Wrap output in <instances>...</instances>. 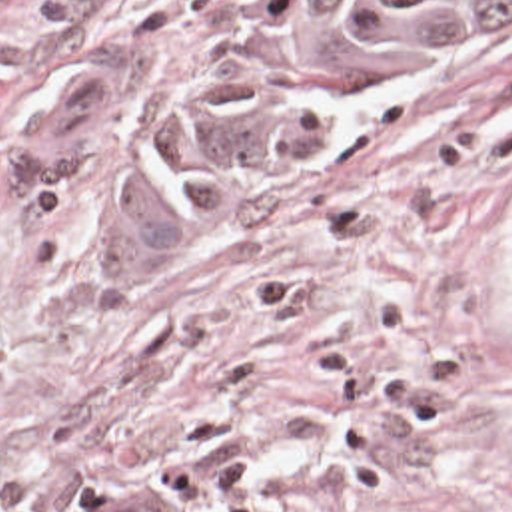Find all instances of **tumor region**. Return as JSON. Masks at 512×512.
<instances>
[{
	"mask_svg": "<svg viewBox=\"0 0 512 512\" xmlns=\"http://www.w3.org/2000/svg\"><path fill=\"white\" fill-rule=\"evenodd\" d=\"M512 41V0H243L213 29L139 143L145 227H213L389 105ZM55 75L17 129L25 189H71L109 145V87ZM69 512H191L97 493Z\"/></svg>",
	"mask_w": 512,
	"mask_h": 512,
	"instance_id": "e687c5a6",
	"label": "tumor region"
}]
</instances>
